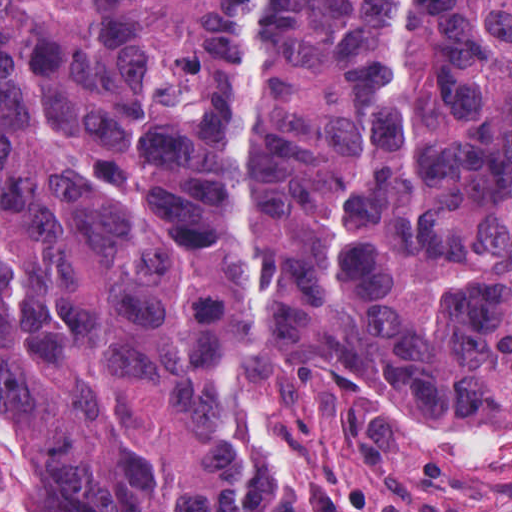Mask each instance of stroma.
I'll use <instances>...</instances> for the list:
<instances>
[{"label": "stroma", "mask_w": 512, "mask_h": 512, "mask_svg": "<svg viewBox=\"0 0 512 512\" xmlns=\"http://www.w3.org/2000/svg\"><path fill=\"white\" fill-rule=\"evenodd\" d=\"M218 396L253 441L234 512H512L510 415L372 397L240 337ZM24 445L0 415V512H24Z\"/></svg>", "instance_id": "stroma-1"}]
</instances>
